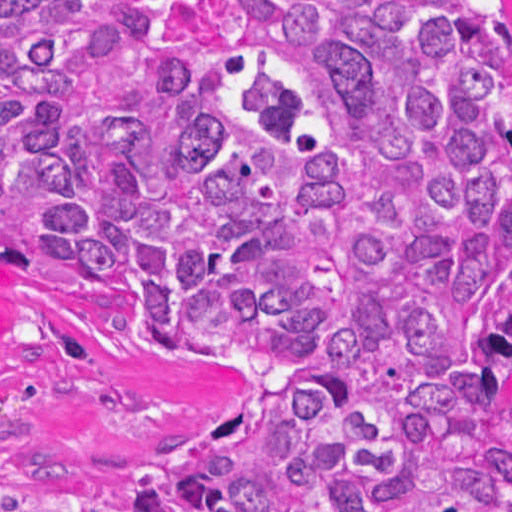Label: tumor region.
I'll return each mask as SVG.
<instances>
[{"mask_svg":"<svg viewBox=\"0 0 512 512\" xmlns=\"http://www.w3.org/2000/svg\"><path fill=\"white\" fill-rule=\"evenodd\" d=\"M0 265L262 388L146 512H512V0H0Z\"/></svg>","mask_w":512,"mask_h":512,"instance_id":"tumor-region-1","label":"tumor region"}]
</instances>
